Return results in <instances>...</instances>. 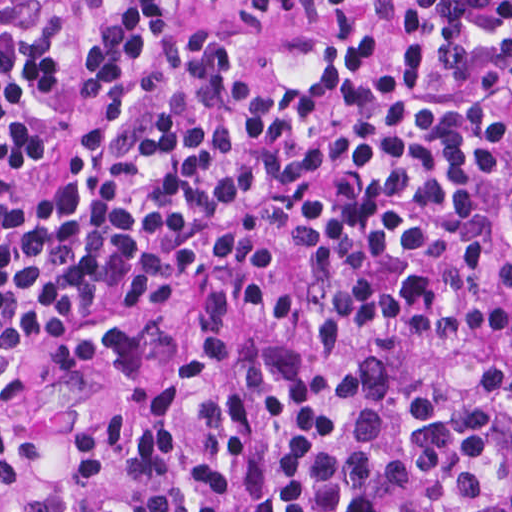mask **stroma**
<instances>
[{
    "mask_svg": "<svg viewBox=\"0 0 512 512\" xmlns=\"http://www.w3.org/2000/svg\"><path fill=\"white\" fill-rule=\"evenodd\" d=\"M212 300L213 299H189L180 304L110 306L87 311L76 319L43 325L25 336L5 343H0V370L17 363L24 356L37 349L74 341L82 335L95 331L107 323L122 321L133 316L152 312H183L194 310L206 306ZM229 300L240 308L249 320L258 328H286L314 323L324 317H336L325 311L268 313L243 301L233 299ZM346 322L358 329L369 341L379 336H404L411 339L437 343L443 339L451 337L432 336L397 328H373L363 323L351 321Z\"/></svg>",
    "mask_w": 512,
    "mask_h": 512,
    "instance_id": "stroma-1",
    "label": "stroma"
}]
</instances>
